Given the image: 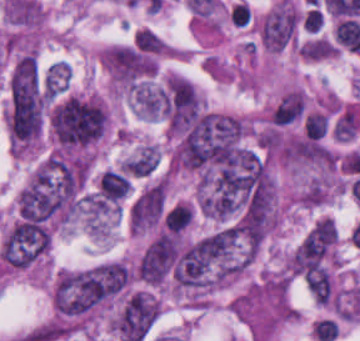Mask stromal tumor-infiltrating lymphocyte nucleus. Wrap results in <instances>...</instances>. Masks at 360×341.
Returning a JSON list of instances; mask_svg holds the SVG:
<instances>
[{
	"instance_id": "52c7bb5b",
	"label": "stromal tumor-infiltrating lymphocyte nucleus",
	"mask_w": 360,
	"mask_h": 341,
	"mask_svg": "<svg viewBox=\"0 0 360 341\" xmlns=\"http://www.w3.org/2000/svg\"><path fill=\"white\" fill-rule=\"evenodd\" d=\"M164 45V40L148 27H141L135 34L134 47L146 54H158Z\"/></svg>"
},
{
	"instance_id": "bc302bb0",
	"label": "stromal tumor-infiltrating lymphocyte nucleus",
	"mask_w": 360,
	"mask_h": 341,
	"mask_svg": "<svg viewBox=\"0 0 360 341\" xmlns=\"http://www.w3.org/2000/svg\"><path fill=\"white\" fill-rule=\"evenodd\" d=\"M305 116V96L301 91L290 90L282 97L271 113L275 125H288Z\"/></svg>"
},
{
	"instance_id": "abfb95fc",
	"label": "stromal tumor-infiltrating lymphocyte nucleus",
	"mask_w": 360,
	"mask_h": 341,
	"mask_svg": "<svg viewBox=\"0 0 360 341\" xmlns=\"http://www.w3.org/2000/svg\"><path fill=\"white\" fill-rule=\"evenodd\" d=\"M228 18L236 26H249L253 22L252 10L243 1H236L228 12Z\"/></svg>"
},
{
	"instance_id": "3290ff9b",
	"label": "stromal tumor-infiltrating lymphocyte nucleus",
	"mask_w": 360,
	"mask_h": 341,
	"mask_svg": "<svg viewBox=\"0 0 360 341\" xmlns=\"http://www.w3.org/2000/svg\"><path fill=\"white\" fill-rule=\"evenodd\" d=\"M328 117L326 113L320 111H312L305 119L306 137L318 139L327 132Z\"/></svg>"
}]
</instances>
